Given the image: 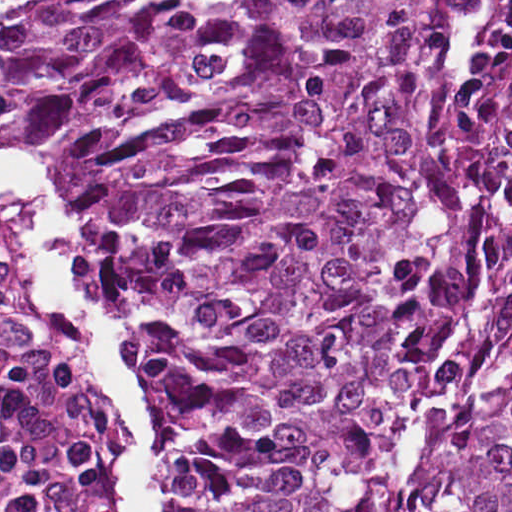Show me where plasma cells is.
Listing matches in <instances>:
<instances>
[{
	"label": "plasma cells",
	"mask_w": 512,
	"mask_h": 512,
	"mask_svg": "<svg viewBox=\"0 0 512 512\" xmlns=\"http://www.w3.org/2000/svg\"><path fill=\"white\" fill-rule=\"evenodd\" d=\"M42 471V435L0 391V512H28Z\"/></svg>",
	"instance_id": "obj_1"
}]
</instances>
